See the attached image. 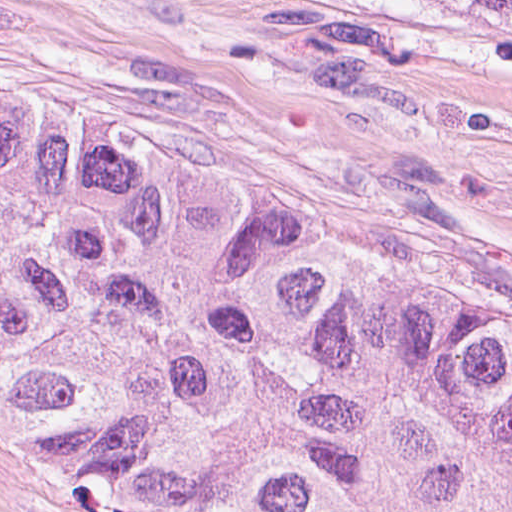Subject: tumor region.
<instances>
[{
	"label": "tumor region",
	"mask_w": 512,
	"mask_h": 512,
	"mask_svg": "<svg viewBox=\"0 0 512 512\" xmlns=\"http://www.w3.org/2000/svg\"><path fill=\"white\" fill-rule=\"evenodd\" d=\"M0 434L165 509L512 512V278L0 96Z\"/></svg>",
	"instance_id": "obj_1"
}]
</instances>
